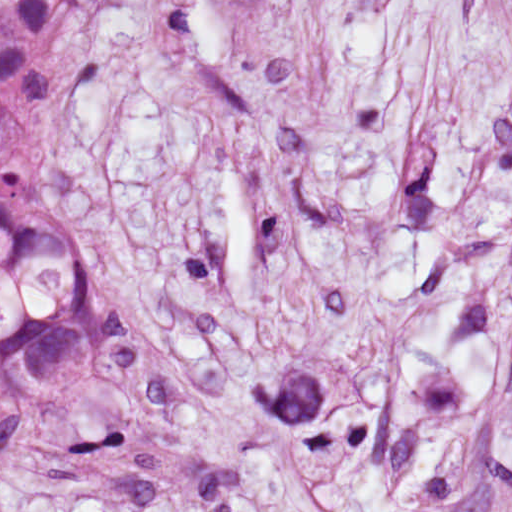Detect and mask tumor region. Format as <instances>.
<instances>
[{
  "instance_id": "e687c5a6",
  "label": "tumor region",
  "mask_w": 512,
  "mask_h": 512,
  "mask_svg": "<svg viewBox=\"0 0 512 512\" xmlns=\"http://www.w3.org/2000/svg\"><path fill=\"white\" fill-rule=\"evenodd\" d=\"M107 0H0V445L84 417L101 355V242L67 152Z\"/></svg>"
}]
</instances>
